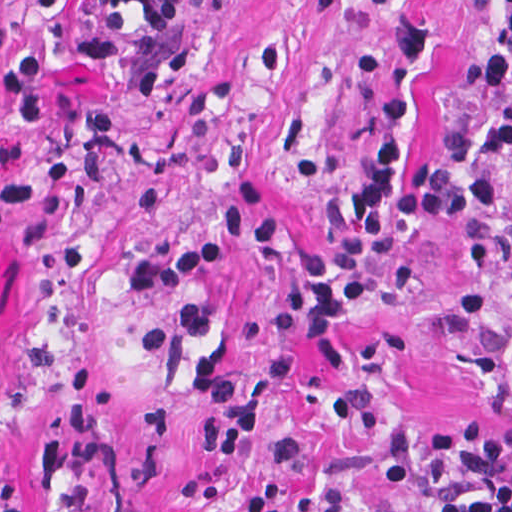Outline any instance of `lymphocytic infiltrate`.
<instances>
[{
	"label": "lymphocytic infiltrate",
	"instance_id": "lymphocytic-infiltrate-1",
	"mask_svg": "<svg viewBox=\"0 0 512 512\" xmlns=\"http://www.w3.org/2000/svg\"><path fill=\"white\" fill-rule=\"evenodd\" d=\"M220 5L221 0H212ZM329 9L358 2L392 16L380 97L363 138L357 176L341 224L307 246L300 258V315L310 350L326 373L348 363L343 313L363 303L373 268L389 250L433 222L449 233L457 265L480 269L501 248V181L512 163V68L505 54L483 59L485 113L469 131L451 134L436 166L407 165L420 74L431 58L429 28L413 0H318ZM501 46L512 56V0ZM52 7L58 0H29ZM178 0H92L82 25L30 48L21 63L0 70V98L9 119L38 122L45 114L48 62L106 60L121 43L123 18L138 14L155 34L171 24ZM431 464L438 500L418 512H512V420L484 418L436 435Z\"/></svg>",
	"mask_w": 512,
	"mask_h": 512
}]
</instances>
